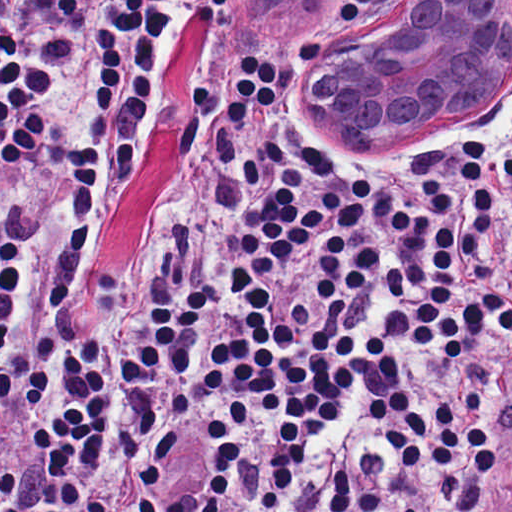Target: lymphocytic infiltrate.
Here are the masks:
<instances>
[{
	"instance_id": "1",
	"label": "lymphocytic infiltrate",
	"mask_w": 512,
	"mask_h": 512,
	"mask_svg": "<svg viewBox=\"0 0 512 512\" xmlns=\"http://www.w3.org/2000/svg\"><path fill=\"white\" fill-rule=\"evenodd\" d=\"M229 2L0 0V468L149 139L0 512H512L509 148L356 152L259 41L169 92Z\"/></svg>"
}]
</instances>
